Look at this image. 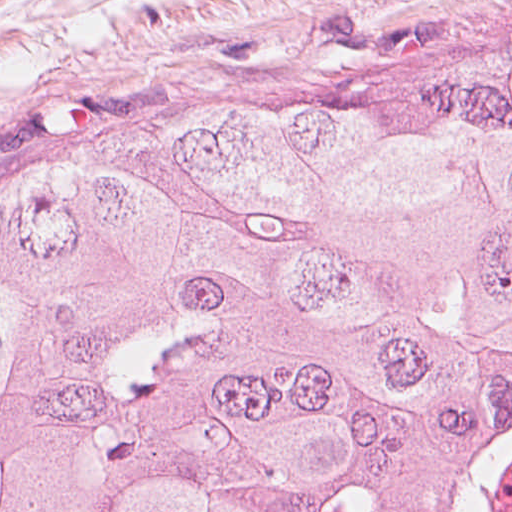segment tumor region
<instances>
[{
  "label": "tumor region",
  "mask_w": 512,
  "mask_h": 512,
  "mask_svg": "<svg viewBox=\"0 0 512 512\" xmlns=\"http://www.w3.org/2000/svg\"><path fill=\"white\" fill-rule=\"evenodd\" d=\"M0 512H512V82L0 219Z\"/></svg>",
  "instance_id": "obj_1"
}]
</instances>
